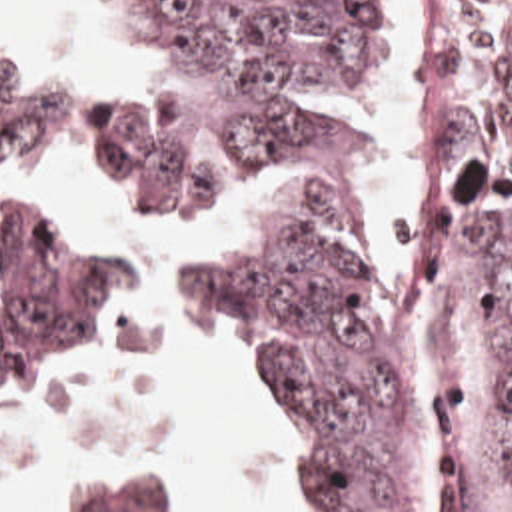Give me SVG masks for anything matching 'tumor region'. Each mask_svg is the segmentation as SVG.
Instances as JSON below:
<instances>
[{"mask_svg":"<svg viewBox=\"0 0 512 512\" xmlns=\"http://www.w3.org/2000/svg\"><path fill=\"white\" fill-rule=\"evenodd\" d=\"M372 0H72V18L142 68L90 100L84 162L124 216L198 226L224 184L314 138L298 110L344 84ZM64 100L0 20V392L66 388L124 356L128 284L88 216L48 194ZM474 262L482 336L512 408V0H454L424 64L416 128V246L394 304ZM200 308L244 344L258 398L286 428L304 512H430L434 452L384 362L378 284L312 216L240 226L232 262L186 268ZM474 394L426 408L456 458L512 512V450L488 472L470 436ZM68 512H190L174 478L90 472Z\"/></svg>","mask_w":512,"mask_h":512,"instance_id":"obj_1","label":"tumor region"}]
</instances>
